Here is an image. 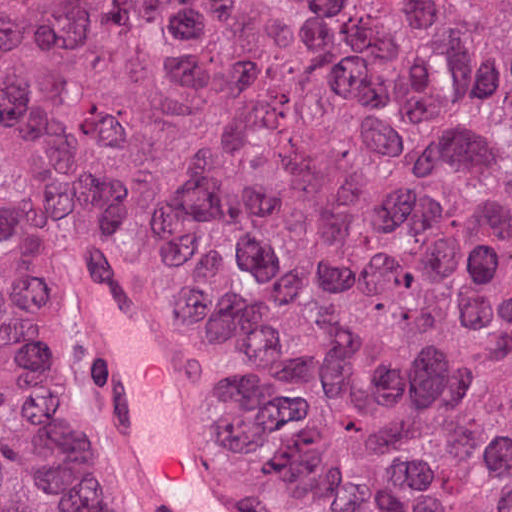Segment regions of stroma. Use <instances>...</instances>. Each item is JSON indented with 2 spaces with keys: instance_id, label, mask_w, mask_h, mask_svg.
<instances>
[{
  "instance_id": "35a3bbf8",
  "label": "stroma",
  "mask_w": 512,
  "mask_h": 512,
  "mask_svg": "<svg viewBox=\"0 0 512 512\" xmlns=\"http://www.w3.org/2000/svg\"><path fill=\"white\" fill-rule=\"evenodd\" d=\"M98 249L111 258H113L125 275L134 285L140 296L143 310L147 316L153 340L160 350L166 364L168 365L177 385L194 407L207 434L213 443V452L218 457L223 471L228 474L236 483H238L252 497L259 501L266 512H277L272 505L239 471L230 454L214 433L208 414L197 396L195 390L181 373L178 366L172 359L164 338L162 336V313L154 296V275L144 263L142 257L133 247V245L112 232H91L79 242L76 243V259L92 249ZM80 358L83 369V375L88 395V378L84 366V328L82 316L80 314ZM88 429L91 443L102 461L110 482L122 501L123 505L128 506L136 512L143 510L134 504L128 497L120 480L106 461L99 444L95 431L92 408L88 396Z\"/></svg>"
}]
</instances>
